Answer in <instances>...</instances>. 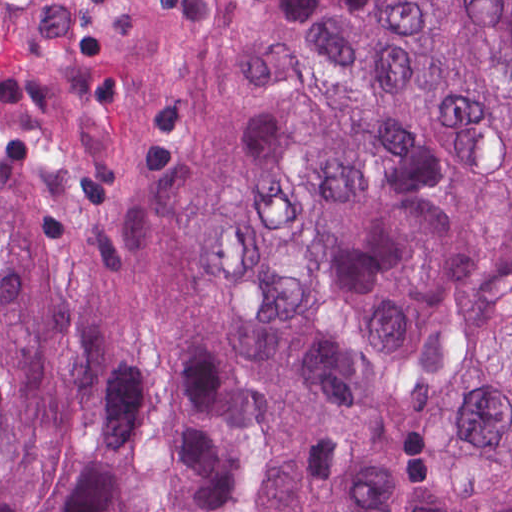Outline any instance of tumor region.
<instances>
[{
  "mask_svg": "<svg viewBox=\"0 0 512 512\" xmlns=\"http://www.w3.org/2000/svg\"><path fill=\"white\" fill-rule=\"evenodd\" d=\"M0 512H512V0H0Z\"/></svg>",
  "mask_w": 512,
  "mask_h": 512,
  "instance_id": "tumor-region-1",
  "label": "tumor region"
}]
</instances>
